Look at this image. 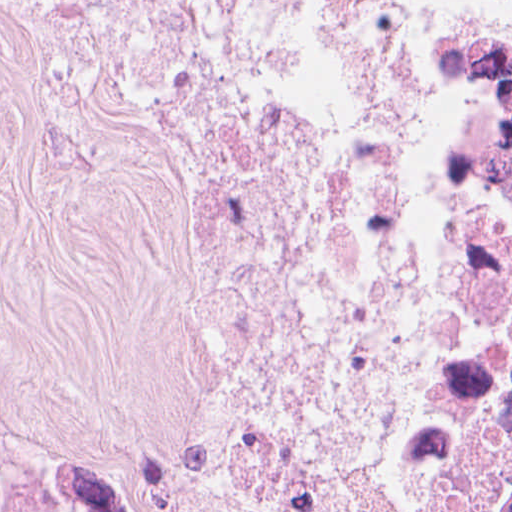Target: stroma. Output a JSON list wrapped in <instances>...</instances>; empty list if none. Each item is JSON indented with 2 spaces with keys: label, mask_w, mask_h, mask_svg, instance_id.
I'll list each match as a JSON object with an SVG mask.
<instances>
[{
  "label": "stroma",
  "mask_w": 512,
  "mask_h": 512,
  "mask_svg": "<svg viewBox=\"0 0 512 512\" xmlns=\"http://www.w3.org/2000/svg\"><path fill=\"white\" fill-rule=\"evenodd\" d=\"M442 2L384 0L397 144L379 316L323 512L340 510L427 211ZM192 311L189 248L129 85L0 0V453L37 512H104L120 464L168 433Z\"/></svg>",
  "instance_id": "35a3bbf8"
}]
</instances>
